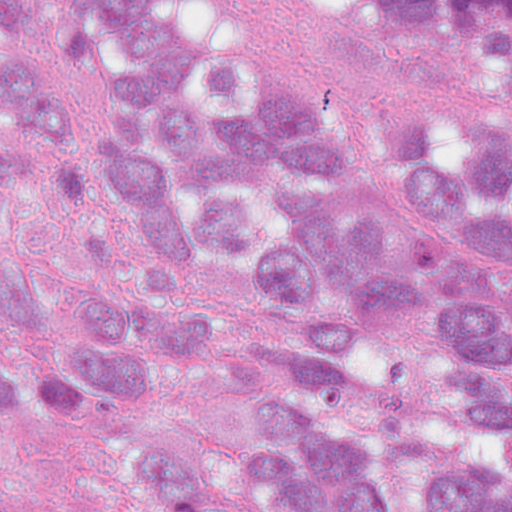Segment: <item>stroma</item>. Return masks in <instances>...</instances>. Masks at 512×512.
<instances>
[{
    "mask_svg": "<svg viewBox=\"0 0 512 512\" xmlns=\"http://www.w3.org/2000/svg\"><path fill=\"white\" fill-rule=\"evenodd\" d=\"M274 22L373 113L443 97H512V62L493 69L465 35L418 30L381 0H288ZM115 488L103 430L65 427L35 438L33 512H87Z\"/></svg>",
    "mask_w": 512,
    "mask_h": 512,
    "instance_id": "1",
    "label": "stroma"
}]
</instances>
